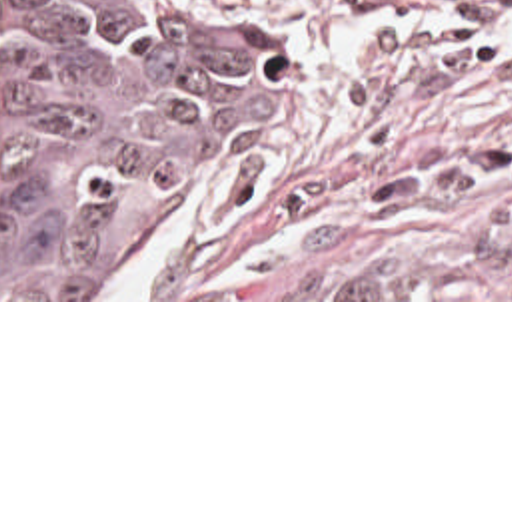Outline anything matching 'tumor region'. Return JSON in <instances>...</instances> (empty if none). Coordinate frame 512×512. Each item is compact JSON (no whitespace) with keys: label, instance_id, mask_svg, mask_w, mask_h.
<instances>
[{"label":"tumor region","instance_id":"e687c5a6","mask_svg":"<svg viewBox=\"0 0 512 512\" xmlns=\"http://www.w3.org/2000/svg\"><path fill=\"white\" fill-rule=\"evenodd\" d=\"M278 100L262 0H0V298H92Z\"/></svg>","mask_w":512,"mask_h":512}]
</instances>
